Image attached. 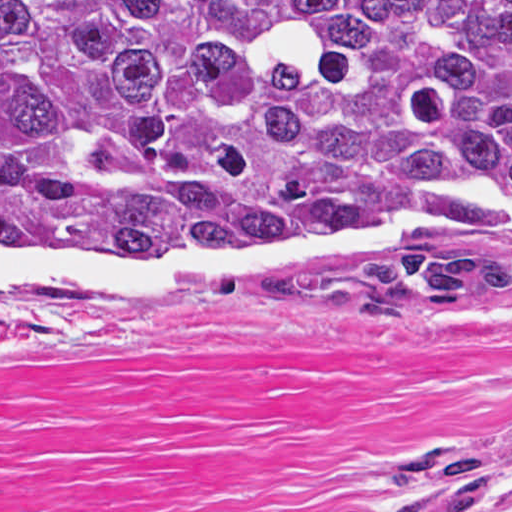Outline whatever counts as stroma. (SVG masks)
Here are the masks:
<instances>
[{"instance_id": "obj_1", "label": "stroma", "mask_w": 512, "mask_h": 512, "mask_svg": "<svg viewBox=\"0 0 512 512\" xmlns=\"http://www.w3.org/2000/svg\"><path fill=\"white\" fill-rule=\"evenodd\" d=\"M415 255L0 306V512H512V303L322 289Z\"/></svg>"}]
</instances>
